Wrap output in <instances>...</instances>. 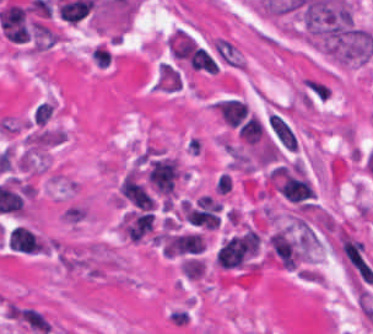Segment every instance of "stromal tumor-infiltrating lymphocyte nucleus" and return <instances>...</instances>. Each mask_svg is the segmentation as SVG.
I'll return each mask as SVG.
<instances>
[{"label":"stromal tumor-infiltrating lymphocyte nucleus","mask_w":373,"mask_h":334,"mask_svg":"<svg viewBox=\"0 0 373 334\" xmlns=\"http://www.w3.org/2000/svg\"><path fill=\"white\" fill-rule=\"evenodd\" d=\"M268 122L279 142L288 150H296L297 143L289 124L272 112L268 117Z\"/></svg>","instance_id":"8"},{"label":"stromal tumor-infiltrating lymphocyte nucleus","mask_w":373,"mask_h":334,"mask_svg":"<svg viewBox=\"0 0 373 334\" xmlns=\"http://www.w3.org/2000/svg\"><path fill=\"white\" fill-rule=\"evenodd\" d=\"M179 164L173 156H159L150 159L145 170V177L164 198H172L179 175Z\"/></svg>","instance_id":"3"},{"label":"stromal tumor-infiltrating lymphocyte nucleus","mask_w":373,"mask_h":334,"mask_svg":"<svg viewBox=\"0 0 373 334\" xmlns=\"http://www.w3.org/2000/svg\"><path fill=\"white\" fill-rule=\"evenodd\" d=\"M260 236L247 229L222 242L215 257L217 267L223 269H256Z\"/></svg>","instance_id":"2"},{"label":"stromal tumor-infiltrating lymphocyte nucleus","mask_w":373,"mask_h":334,"mask_svg":"<svg viewBox=\"0 0 373 334\" xmlns=\"http://www.w3.org/2000/svg\"><path fill=\"white\" fill-rule=\"evenodd\" d=\"M213 108L221 120L229 125H238L246 115L245 102L239 97H226L213 102Z\"/></svg>","instance_id":"7"},{"label":"stromal tumor-infiltrating lymphocyte nucleus","mask_w":373,"mask_h":334,"mask_svg":"<svg viewBox=\"0 0 373 334\" xmlns=\"http://www.w3.org/2000/svg\"><path fill=\"white\" fill-rule=\"evenodd\" d=\"M268 257L285 269H293L302 259V250L287 225L271 233Z\"/></svg>","instance_id":"4"},{"label":"stromal tumor-infiltrating lymphocyte nucleus","mask_w":373,"mask_h":334,"mask_svg":"<svg viewBox=\"0 0 373 334\" xmlns=\"http://www.w3.org/2000/svg\"><path fill=\"white\" fill-rule=\"evenodd\" d=\"M266 188L295 204H302L313 197V187L300 160L274 165L267 177Z\"/></svg>","instance_id":"1"},{"label":"stromal tumor-infiltrating lymphocyte nucleus","mask_w":373,"mask_h":334,"mask_svg":"<svg viewBox=\"0 0 373 334\" xmlns=\"http://www.w3.org/2000/svg\"><path fill=\"white\" fill-rule=\"evenodd\" d=\"M116 202L135 208L151 209L152 207L153 200L146 186L137 170L131 166L119 183Z\"/></svg>","instance_id":"5"},{"label":"stromal tumor-infiltrating lymphocyte nucleus","mask_w":373,"mask_h":334,"mask_svg":"<svg viewBox=\"0 0 373 334\" xmlns=\"http://www.w3.org/2000/svg\"><path fill=\"white\" fill-rule=\"evenodd\" d=\"M152 226V213L144 210L124 212L118 222V232L130 242H137L147 234Z\"/></svg>","instance_id":"6"}]
</instances>
